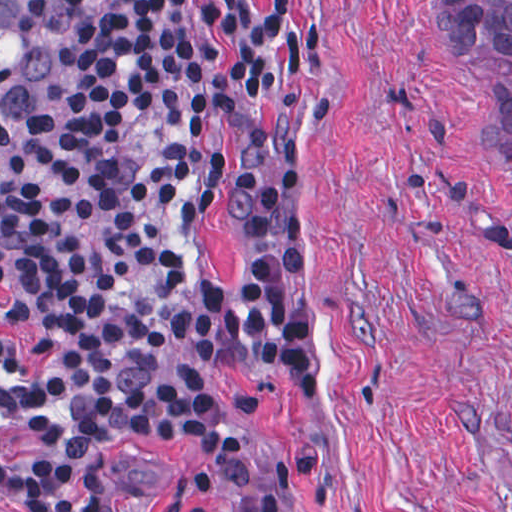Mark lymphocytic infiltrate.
<instances>
[{
    "instance_id": "f902f5d3",
    "label": "lymphocytic infiltrate",
    "mask_w": 512,
    "mask_h": 512,
    "mask_svg": "<svg viewBox=\"0 0 512 512\" xmlns=\"http://www.w3.org/2000/svg\"><path fill=\"white\" fill-rule=\"evenodd\" d=\"M43 1L68 22L63 70L51 104L0 143V324L37 344L35 369L0 364V417L28 426L0 443V496L23 512H124L106 451L170 440L225 512H292L201 378L156 357L179 334L187 239L213 198L209 87L225 51V210L242 249L197 283V359L285 404L311 399V340L289 309L302 179L268 163L260 136L316 76L304 17L319 0Z\"/></svg>"
}]
</instances>
